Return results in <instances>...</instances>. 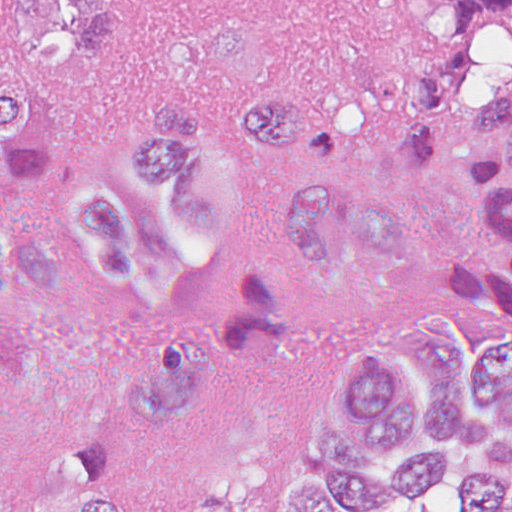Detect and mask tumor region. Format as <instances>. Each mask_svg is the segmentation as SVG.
Segmentation results:
<instances>
[{
	"instance_id": "e687c5a6",
	"label": "tumor region",
	"mask_w": 512,
	"mask_h": 512,
	"mask_svg": "<svg viewBox=\"0 0 512 512\" xmlns=\"http://www.w3.org/2000/svg\"><path fill=\"white\" fill-rule=\"evenodd\" d=\"M417 14L445 40L442 62L400 76L387 141L419 166L447 132L470 121L474 185L494 222V250L431 258L427 278L452 305L512 335V71L493 108L458 103L469 43L512 0H365ZM115 40V0H22L0 11V458L29 401L33 343L11 292L43 287L53 258L15 221L12 195L53 163L48 91L99 62ZM310 131L301 92H265L225 123L174 102L125 131L117 178H83L58 203L71 254L123 295L172 303L223 291L217 327L151 361L126 415L107 435L69 447L58 485L29 509L0 495V512H133L132 474L173 444L197 408L228 386H262L294 358L306 303H347L396 279L406 264L395 211L331 171L294 186L271 234L255 240L259 182ZM401 339L437 397L412 398L383 350L353 353L334 380L343 425L313 426L321 483L290 489L283 512H376L458 481L467 512L512 505V341L482 363L468 335L418 317Z\"/></svg>"
}]
</instances>
